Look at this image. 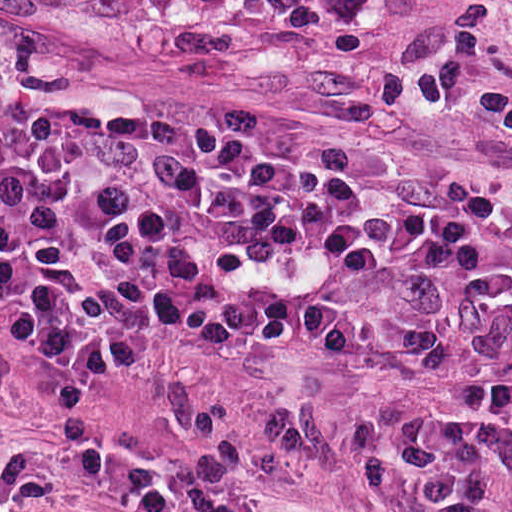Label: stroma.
Masks as SVG:
<instances>
[{
  "label": "stroma",
  "instance_id": "stroma-1",
  "mask_svg": "<svg viewBox=\"0 0 512 512\" xmlns=\"http://www.w3.org/2000/svg\"><path fill=\"white\" fill-rule=\"evenodd\" d=\"M0 125L346 182L512 190V0H0ZM164 340L229 419L43 384L0 330V512H512L461 392L357 341Z\"/></svg>",
  "mask_w": 512,
  "mask_h": 512
}]
</instances>
